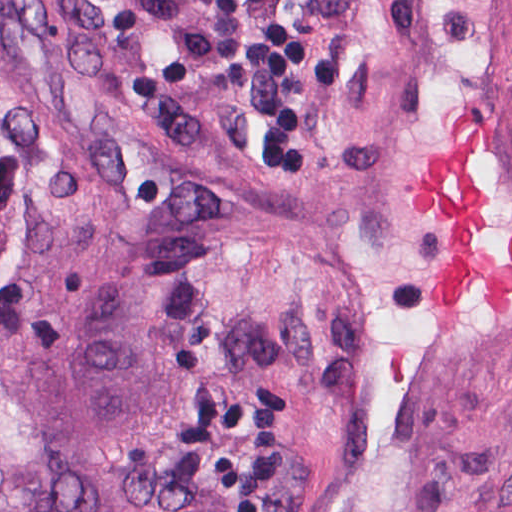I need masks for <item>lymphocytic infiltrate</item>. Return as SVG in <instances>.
I'll return each instance as SVG.
<instances>
[{
  "label": "lymphocytic infiltrate",
  "instance_id": "1",
  "mask_svg": "<svg viewBox=\"0 0 512 512\" xmlns=\"http://www.w3.org/2000/svg\"><path fill=\"white\" fill-rule=\"evenodd\" d=\"M340 0H266V39L249 123L274 163L296 152L325 85Z\"/></svg>",
  "mask_w": 512,
  "mask_h": 512
}]
</instances>
